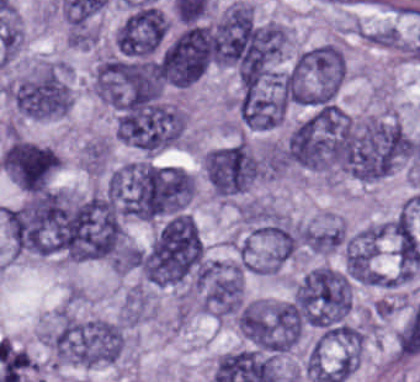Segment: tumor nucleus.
Returning <instances> with one entry per match:
<instances>
[{
	"instance_id": "6",
	"label": "tumor nucleus",
	"mask_w": 420,
	"mask_h": 382,
	"mask_svg": "<svg viewBox=\"0 0 420 382\" xmlns=\"http://www.w3.org/2000/svg\"><path fill=\"white\" fill-rule=\"evenodd\" d=\"M185 126L184 110L165 100L137 95L117 106L116 137L141 153L174 147Z\"/></svg>"
},
{
	"instance_id": "14",
	"label": "tumor nucleus",
	"mask_w": 420,
	"mask_h": 382,
	"mask_svg": "<svg viewBox=\"0 0 420 382\" xmlns=\"http://www.w3.org/2000/svg\"><path fill=\"white\" fill-rule=\"evenodd\" d=\"M244 300L239 261L212 259L199 281V309L219 320L236 314Z\"/></svg>"
},
{
	"instance_id": "8",
	"label": "tumor nucleus",
	"mask_w": 420,
	"mask_h": 382,
	"mask_svg": "<svg viewBox=\"0 0 420 382\" xmlns=\"http://www.w3.org/2000/svg\"><path fill=\"white\" fill-rule=\"evenodd\" d=\"M125 330L117 321L101 317L64 316L58 328V357L62 364L97 367L118 361Z\"/></svg>"
},
{
	"instance_id": "1",
	"label": "tumor nucleus",
	"mask_w": 420,
	"mask_h": 382,
	"mask_svg": "<svg viewBox=\"0 0 420 382\" xmlns=\"http://www.w3.org/2000/svg\"><path fill=\"white\" fill-rule=\"evenodd\" d=\"M332 167L360 182L391 174L410 152L405 128L389 116L328 115Z\"/></svg>"
},
{
	"instance_id": "16",
	"label": "tumor nucleus",
	"mask_w": 420,
	"mask_h": 382,
	"mask_svg": "<svg viewBox=\"0 0 420 382\" xmlns=\"http://www.w3.org/2000/svg\"><path fill=\"white\" fill-rule=\"evenodd\" d=\"M237 112L248 128L270 130L282 122L284 98L274 81L244 83L238 96Z\"/></svg>"
},
{
	"instance_id": "4",
	"label": "tumor nucleus",
	"mask_w": 420,
	"mask_h": 382,
	"mask_svg": "<svg viewBox=\"0 0 420 382\" xmlns=\"http://www.w3.org/2000/svg\"><path fill=\"white\" fill-rule=\"evenodd\" d=\"M306 224L264 206L241 209L240 253L247 272L273 275L297 252Z\"/></svg>"
},
{
	"instance_id": "7",
	"label": "tumor nucleus",
	"mask_w": 420,
	"mask_h": 382,
	"mask_svg": "<svg viewBox=\"0 0 420 382\" xmlns=\"http://www.w3.org/2000/svg\"><path fill=\"white\" fill-rule=\"evenodd\" d=\"M291 301L302 323L324 330L345 322L352 291L343 269L315 266L296 281Z\"/></svg>"
},
{
	"instance_id": "13",
	"label": "tumor nucleus",
	"mask_w": 420,
	"mask_h": 382,
	"mask_svg": "<svg viewBox=\"0 0 420 382\" xmlns=\"http://www.w3.org/2000/svg\"><path fill=\"white\" fill-rule=\"evenodd\" d=\"M59 162L49 144L12 137L0 155V170L19 189L36 191L49 185Z\"/></svg>"
},
{
	"instance_id": "3",
	"label": "tumor nucleus",
	"mask_w": 420,
	"mask_h": 382,
	"mask_svg": "<svg viewBox=\"0 0 420 382\" xmlns=\"http://www.w3.org/2000/svg\"><path fill=\"white\" fill-rule=\"evenodd\" d=\"M142 279L156 288L181 289L196 279L203 266L201 233L191 216L168 221L140 248Z\"/></svg>"
},
{
	"instance_id": "9",
	"label": "tumor nucleus",
	"mask_w": 420,
	"mask_h": 382,
	"mask_svg": "<svg viewBox=\"0 0 420 382\" xmlns=\"http://www.w3.org/2000/svg\"><path fill=\"white\" fill-rule=\"evenodd\" d=\"M17 115L50 120L65 115L73 92L65 62L43 60L6 87Z\"/></svg>"
},
{
	"instance_id": "5",
	"label": "tumor nucleus",
	"mask_w": 420,
	"mask_h": 382,
	"mask_svg": "<svg viewBox=\"0 0 420 382\" xmlns=\"http://www.w3.org/2000/svg\"><path fill=\"white\" fill-rule=\"evenodd\" d=\"M1 218L11 258H62L58 189L26 196Z\"/></svg>"
},
{
	"instance_id": "15",
	"label": "tumor nucleus",
	"mask_w": 420,
	"mask_h": 382,
	"mask_svg": "<svg viewBox=\"0 0 420 382\" xmlns=\"http://www.w3.org/2000/svg\"><path fill=\"white\" fill-rule=\"evenodd\" d=\"M169 27L162 10L141 4L124 16L114 31L116 53L125 58L148 59L159 48Z\"/></svg>"
},
{
	"instance_id": "12",
	"label": "tumor nucleus",
	"mask_w": 420,
	"mask_h": 382,
	"mask_svg": "<svg viewBox=\"0 0 420 382\" xmlns=\"http://www.w3.org/2000/svg\"><path fill=\"white\" fill-rule=\"evenodd\" d=\"M202 172L217 198H232L258 182L261 164L252 148L236 141L206 151L201 156Z\"/></svg>"
},
{
	"instance_id": "2",
	"label": "tumor nucleus",
	"mask_w": 420,
	"mask_h": 382,
	"mask_svg": "<svg viewBox=\"0 0 420 382\" xmlns=\"http://www.w3.org/2000/svg\"><path fill=\"white\" fill-rule=\"evenodd\" d=\"M349 114L320 105L290 130L285 163L326 180L345 174Z\"/></svg>"
},
{
	"instance_id": "11",
	"label": "tumor nucleus",
	"mask_w": 420,
	"mask_h": 382,
	"mask_svg": "<svg viewBox=\"0 0 420 382\" xmlns=\"http://www.w3.org/2000/svg\"><path fill=\"white\" fill-rule=\"evenodd\" d=\"M243 336L270 353H284L300 341L299 310L291 300L249 298L238 313Z\"/></svg>"
},
{
	"instance_id": "17",
	"label": "tumor nucleus",
	"mask_w": 420,
	"mask_h": 382,
	"mask_svg": "<svg viewBox=\"0 0 420 382\" xmlns=\"http://www.w3.org/2000/svg\"><path fill=\"white\" fill-rule=\"evenodd\" d=\"M302 237L310 252L329 254L343 246L347 233L344 222L330 219L305 225Z\"/></svg>"
},
{
	"instance_id": "10",
	"label": "tumor nucleus",
	"mask_w": 420,
	"mask_h": 382,
	"mask_svg": "<svg viewBox=\"0 0 420 382\" xmlns=\"http://www.w3.org/2000/svg\"><path fill=\"white\" fill-rule=\"evenodd\" d=\"M345 77V55L339 44L301 50L286 72L289 100L302 105L332 101Z\"/></svg>"
}]
</instances>
